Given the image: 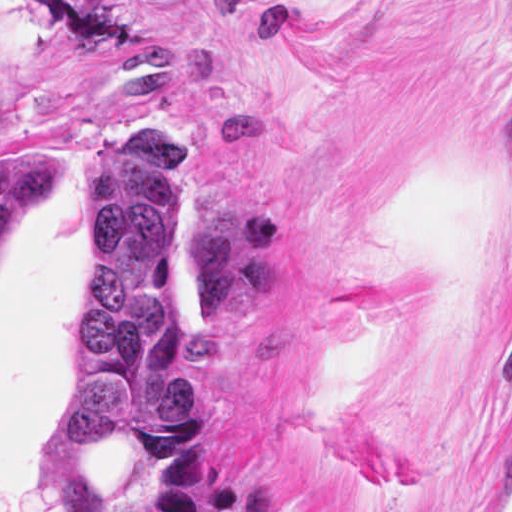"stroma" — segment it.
Wrapping results in <instances>:
<instances>
[{"label":"stroma","mask_w":512,"mask_h":512,"mask_svg":"<svg viewBox=\"0 0 512 512\" xmlns=\"http://www.w3.org/2000/svg\"><path fill=\"white\" fill-rule=\"evenodd\" d=\"M0 96L51 161L0 242V512H53L86 174L137 119L185 168L193 403L96 498L469 509L512 437V0H0Z\"/></svg>","instance_id":"1"}]
</instances>
